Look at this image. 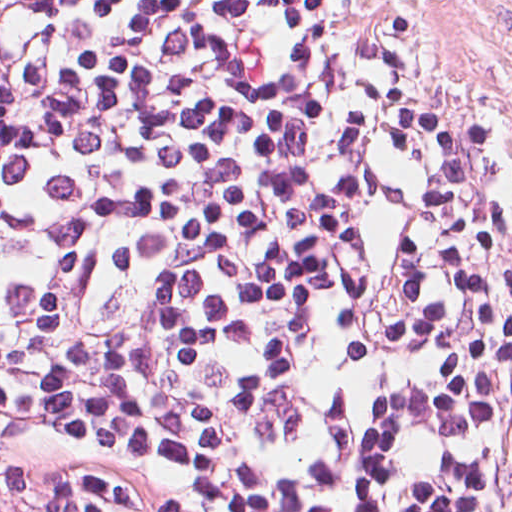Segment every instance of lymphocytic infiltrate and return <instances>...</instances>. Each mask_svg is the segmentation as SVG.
<instances>
[{"instance_id":"f902f5d3","label":"lymphocytic infiltrate","mask_w":512,"mask_h":512,"mask_svg":"<svg viewBox=\"0 0 512 512\" xmlns=\"http://www.w3.org/2000/svg\"><path fill=\"white\" fill-rule=\"evenodd\" d=\"M0 512H512L390 0H0Z\"/></svg>"}]
</instances>
